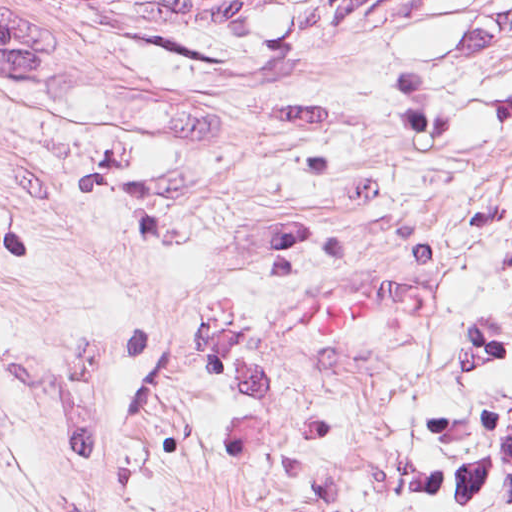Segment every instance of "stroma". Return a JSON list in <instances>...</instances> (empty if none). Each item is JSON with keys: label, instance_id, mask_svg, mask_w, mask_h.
<instances>
[{"label": "stroma", "instance_id": "stroma-1", "mask_svg": "<svg viewBox=\"0 0 512 512\" xmlns=\"http://www.w3.org/2000/svg\"><path fill=\"white\" fill-rule=\"evenodd\" d=\"M128 0H0V512H20Z\"/></svg>", "mask_w": 512, "mask_h": 512}]
</instances>
